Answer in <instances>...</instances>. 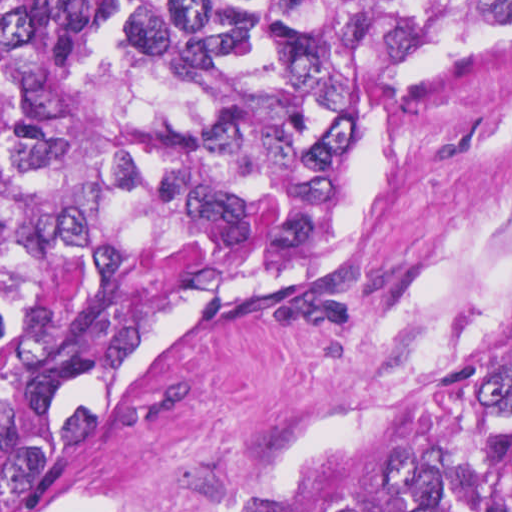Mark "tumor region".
Instances as JSON below:
<instances>
[{"instance_id":"e687c5a6","label":"tumor region","mask_w":512,"mask_h":512,"mask_svg":"<svg viewBox=\"0 0 512 512\" xmlns=\"http://www.w3.org/2000/svg\"><path fill=\"white\" fill-rule=\"evenodd\" d=\"M511 32L512 0H19L0 20V512H512V317L205 506L19 511L153 333L322 263L371 98Z\"/></svg>"}]
</instances>
